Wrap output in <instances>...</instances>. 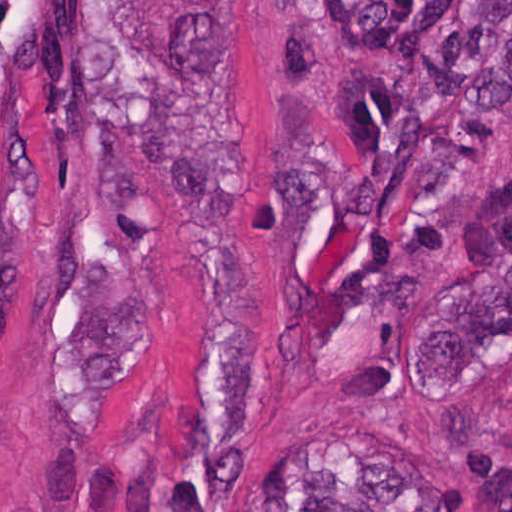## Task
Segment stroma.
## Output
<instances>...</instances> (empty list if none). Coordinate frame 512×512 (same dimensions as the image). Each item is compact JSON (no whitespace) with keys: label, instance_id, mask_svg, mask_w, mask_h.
<instances>
[{"label":"stroma","instance_id":"obj_1","mask_svg":"<svg viewBox=\"0 0 512 512\" xmlns=\"http://www.w3.org/2000/svg\"><path fill=\"white\" fill-rule=\"evenodd\" d=\"M46 1L0 185V512H145L184 451L194 252L149 186L103 1H198L240 222L254 372L227 512L279 480L430 470L512 512V349L449 344L512 211V93L430 167L362 275L370 225L302 222L285 1Z\"/></svg>","mask_w":512,"mask_h":512}]
</instances>
